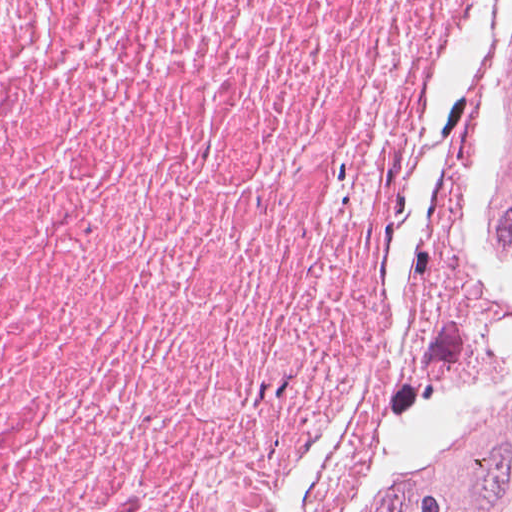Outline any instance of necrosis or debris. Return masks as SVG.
Returning <instances> with one entry per match:
<instances>
[{
  "mask_svg": "<svg viewBox=\"0 0 512 512\" xmlns=\"http://www.w3.org/2000/svg\"><path fill=\"white\" fill-rule=\"evenodd\" d=\"M499 2L0 0V512H395L512 346Z\"/></svg>",
  "mask_w": 512,
  "mask_h": 512,
  "instance_id": "1",
  "label": "necrosis or debris"
}]
</instances>
